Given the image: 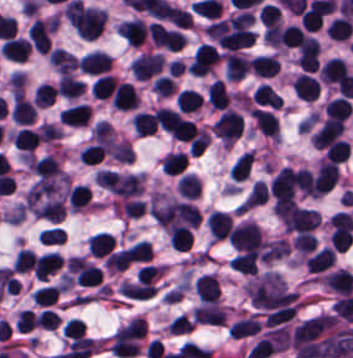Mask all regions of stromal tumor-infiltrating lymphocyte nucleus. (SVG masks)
<instances>
[{
    "mask_svg": "<svg viewBox=\"0 0 353 358\" xmlns=\"http://www.w3.org/2000/svg\"><path fill=\"white\" fill-rule=\"evenodd\" d=\"M58 325V315L50 309H43L38 315L37 326L43 329H56Z\"/></svg>",
    "mask_w": 353,
    "mask_h": 358,
    "instance_id": "4aeada98",
    "label": "stromal tumor-infiltrating lymphocyte nucleus"
},
{
    "mask_svg": "<svg viewBox=\"0 0 353 358\" xmlns=\"http://www.w3.org/2000/svg\"><path fill=\"white\" fill-rule=\"evenodd\" d=\"M116 81L110 74H102L97 78L91 88V94L96 98H110Z\"/></svg>",
    "mask_w": 353,
    "mask_h": 358,
    "instance_id": "16295066",
    "label": "stromal tumor-infiltrating lymphocyte nucleus"
},
{
    "mask_svg": "<svg viewBox=\"0 0 353 358\" xmlns=\"http://www.w3.org/2000/svg\"><path fill=\"white\" fill-rule=\"evenodd\" d=\"M339 170L335 163L329 160L321 161L313 182L314 196H322L335 184Z\"/></svg>",
    "mask_w": 353,
    "mask_h": 358,
    "instance_id": "4f13568d",
    "label": "stromal tumor-infiltrating lymphocyte nucleus"
},
{
    "mask_svg": "<svg viewBox=\"0 0 353 358\" xmlns=\"http://www.w3.org/2000/svg\"><path fill=\"white\" fill-rule=\"evenodd\" d=\"M164 63L162 54L143 52L132 62V71L137 80H146L157 74Z\"/></svg>",
    "mask_w": 353,
    "mask_h": 358,
    "instance_id": "9ea309e8",
    "label": "stromal tumor-infiltrating lymphocyte nucleus"
},
{
    "mask_svg": "<svg viewBox=\"0 0 353 358\" xmlns=\"http://www.w3.org/2000/svg\"><path fill=\"white\" fill-rule=\"evenodd\" d=\"M221 58L220 51L209 44L197 48L188 64L192 75H205Z\"/></svg>",
    "mask_w": 353,
    "mask_h": 358,
    "instance_id": "3290ff9b",
    "label": "stromal tumor-infiltrating lymphocyte nucleus"
},
{
    "mask_svg": "<svg viewBox=\"0 0 353 358\" xmlns=\"http://www.w3.org/2000/svg\"><path fill=\"white\" fill-rule=\"evenodd\" d=\"M106 153L101 143H94L80 150L79 157L86 164H96L101 161Z\"/></svg>",
    "mask_w": 353,
    "mask_h": 358,
    "instance_id": "894b7857",
    "label": "stromal tumor-infiltrating lymphocyte nucleus"
},
{
    "mask_svg": "<svg viewBox=\"0 0 353 358\" xmlns=\"http://www.w3.org/2000/svg\"><path fill=\"white\" fill-rule=\"evenodd\" d=\"M111 60L106 51L94 50L79 60V67L86 73L101 75L110 71Z\"/></svg>",
    "mask_w": 353,
    "mask_h": 358,
    "instance_id": "4803ca6d",
    "label": "stromal tumor-infiltrating lymphocyte nucleus"
},
{
    "mask_svg": "<svg viewBox=\"0 0 353 358\" xmlns=\"http://www.w3.org/2000/svg\"><path fill=\"white\" fill-rule=\"evenodd\" d=\"M35 321L34 313L29 309H22L16 318V329L30 331Z\"/></svg>",
    "mask_w": 353,
    "mask_h": 358,
    "instance_id": "d76ffc17",
    "label": "stromal tumor-infiltrating lymphocyte nucleus"
},
{
    "mask_svg": "<svg viewBox=\"0 0 353 358\" xmlns=\"http://www.w3.org/2000/svg\"><path fill=\"white\" fill-rule=\"evenodd\" d=\"M202 99L198 91L183 88L176 96V105L182 113H190L198 109Z\"/></svg>",
    "mask_w": 353,
    "mask_h": 358,
    "instance_id": "023d44f5",
    "label": "stromal tumor-infiltrating lymphocyte nucleus"
},
{
    "mask_svg": "<svg viewBox=\"0 0 353 358\" xmlns=\"http://www.w3.org/2000/svg\"><path fill=\"white\" fill-rule=\"evenodd\" d=\"M353 106L349 97L338 96L327 106V115L329 118L347 119L349 118Z\"/></svg>",
    "mask_w": 353,
    "mask_h": 358,
    "instance_id": "afbf053c",
    "label": "stromal tumor-infiltrating lymphocyte nucleus"
},
{
    "mask_svg": "<svg viewBox=\"0 0 353 358\" xmlns=\"http://www.w3.org/2000/svg\"><path fill=\"white\" fill-rule=\"evenodd\" d=\"M262 328L257 315H250L234 323L228 330L230 337L244 338L255 335Z\"/></svg>",
    "mask_w": 353,
    "mask_h": 358,
    "instance_id": "7eef579d",
    "label": "stromal tumor-infiltrating lymphocyte nucleus"
},
{
    "mask_svg": "<svg viewBox=\"0 0 353 358\" xmlns=\"http://www.w3.org/2000/svg\"><path fill=\"white\" fill-rule=\"evenodd\" d=\"M251 113L262 133L278 138V121L275 114L261 108H254Z\"/></svg>",
    "mask_w": 353,
    "mask_h": 358,
    "instance_id": "a0a3295f",
    "label": "stromal tumor-infiltrating lymphocyte nucleus"
},
{
    "mask_svg": "<svg viewBox=\"0 0 353 358\" xmlns=\"http://www.w3.org/2000/svg\"><path fill=\"white\" fill-rule=\"evenodd\" d=\"M194 289L202 303L219 300V282L211 273H204L195 278Z\"/></svg>",
    "mask_w": 353,
    "mask_h": 358,
    "instance_id": "4c9ddf68",
    "label": "stromal tumor-infiltrating lymphocyte nucleus"
},
{
    "mask_svg": "<svg viewBox=\"0 0 353 358\" xmlns=\"http://www.w3.org/2000/svg\"><path fill=\"white\" fill-rule=\"evenodd\" d=\"M14 145L24 150H34L41 138L35 129L22 128L12 136Z\"/></svg>",
    "mask_w": 353,
    "mask_h": 358,
    "instance_id": "84afeb40",
    "label": "stromal tumor-infiltrating lymphocyte nucleus"
},
{
    "mask_svg": "<svg viewBox=\"0 0 353 358\" xmlns=\"http://www.w3.org/2000/svg\"><path fill=\"white\" fill-rule=\"evenodd\" d=\"M31 47L27 40L19 36H12L0 45L3 57L14 61H25Z\"/></svg>",
    "mask_w": 353,
    "mask_h": 358,
    "instance_id": "42bb06b2",
    "label": "stromal tumor-infiltrating lymphocyte nucleus"
},
{
    "mask_svg": "<svg viewBox=\"0 0 353 358\" xmlns=\"http://www.w3.org/2000/svg\"><path fill=\"white\" fill-rule=\"evenodd\" d=\"M116 240L110 232H96L89 242V248L97 257H105L115 248Z\"/></svg>",
    "mask_w": 353,
    "mask_h": 358,
    "instance_id": "6c763739",
    "label": "stromal tumor-infiltrating lymphocyte nucleus"
},
{
    "mask_svg": "<svg viewBox=\"0 0 353 358\" xmlns=\"http://www.w3.org/2000/svg\"><path fill=\"white\" fill-rule=\"evenodd\" d=\"M91 190L85 184H78L69 193V207L70 210L79 211L80 209L89 205Z\"/></svg>",
    "mask_w": 353,
    "mask_h": 358,
    "instance_id": "a6e9041d",
    "label": "stromal tumor-infiltrating lymphocyte nucleus"
},
{
    "mask_svg": "<svg viewBox=\"0 0 353 358\" xmlns=\"http://www.w3.org/2000/svg\"><path fill=\"white\" fill-rule=\"evenodd\" d=\"M160 274H162L160 266L152 265L148 263L138 268L136 272L138 283H143V284L151 280H154Z\"/></svg>",
    "mask_w": 353,
    "mask_h": 358,
    "instance_id": "0ca4a824",
    "label": "stromal tumor-infiltrating lymphocyte nucleus"
},
{
    "mask_svg": "<svg viewBox=\"0 0 353 358\" xmlns=\"http://www.w3.org/2000/svg\"><path fill=\"white\" fill-rule=\"evenodd\" d=\"M52 32L53 20L51 18H35L30 26L28 39L35 50L48 52Z\"/></svg>",
    "mask_w": 353,
    "mask_h": 358,
    "instance_id": "abfb95fc",
    "label": "stromal tumor-infiltrating lymphocyte nucleus"
},
{
    "mask_svg": "<svg viewBox=\"0 0 353 358\" xmlns=\"http://www.w3.org/2000/svg\"><path fill=\"white\" fill-rule=\"evenodd\" d=\"M56 97V88L54 85L42 83L33 95V103L37 108L50 106Z\"/></svg>",
    "mask_w": 353,
    "mask_h": 358,
    "instance_id": "ccc9de39",
    "label": "stromal tumor-infiltrating lymphocyte nucleus"
},
{
    "mask_svg": "<svg viewBox=\"0 0 353 358\" xmlns=\"http://www.w3.org/2000/svg\"><path fill=\"white\" fill-rule=\"evenodd\" d=\"M35 255L28 248H21L15 257L13 268L17 272H25L33 268Z\"/></svg>",
    "mask_w": 353,
    "mask_h": 358,
    "instance_id": "fb6c686a",
    "label": "stromal tumor-infiltrating lymphocyte nucleus"
},
{
    "mask_svg": "<svg viewBox=\"0 0 353 358\" xmlns=\"http://www.w3.org/2000/svg\"><path fill=\"white\" fill-rule=\"evenodd\" d=\"M86 323L77 318H70L63 328V335L69 338L84 336Z\"/></svg>",
    "mask_w": 353,
    "mask_h": 358,
    "instance_id": "b01e43ef",
    "label": "stromal tumor-infiltrating lymphocyte nucleus"
},
{
    "mask_svg": "<svg viewBox=\"0 0 353 358\" xmlns=\"http://www.w3.org/2000/svg\"><path fill=\"white\" fill-rule=\"evenodd\" d=\"M344 121L326 119L313 133V143L319 148H327L342 139Z\"/></svg>",
    "mask_w": 353,
    "mask_h": 358,
    "instance_id": "f3e2335f",
    "label": "stromal tumor-infiltrating lymphocyte nucleus"
},
{
    "mask_svg": "<svg viewBox=\"0 0 353 358\" xmlns=\"http://www.w3.org/2000/svg\"><path fill=\"white\" fill-rule=\"evenodd\" d=\"M292 90L296 97L314 101L319 94V84L314 76L301 72L292 82Z\"/></svg>",
    "mask_w": 353,
    "mask_h": 358,
    "instance_id": "9e4306bb",
    "label": "stromal tumor-infiltrating lymphocyte nucleus"
},
{
    "mask_svg": "<svg viewBox=\"0 0 353 358\" xmlns=\"http://www.w3.org/2000/svg\"><path fill=\"white\" fill-rule=\"evenodd\" d=\"M228 238L235 249L258 251L265 243L260 225L250 220L231 229Z\"/></svg>",
    "mask_w": 353,
    "mask_h": 358,
    "instance_id": "bc302bb0",
    "label": "stromal tumor-infiltrating lymphocyte nucleus"
},
{
    "mask_svg": "<svg viewBox=\"0 0 353 358\" xmlns=\"http://www.w3.org/2000/svg\"><path fill=\"white\" fill-rule=\"evenodd\" d=\"M85 88V82L71 74L70 72L60 76L58 85L59 96L65 98H79Z\"/></svg>",
    "mask_w": 353,
    "mask_h": 358,
    "instance_id": "3e0999b9",
    "label": "stromal tumor-infiltrating lymphocyte nucleus"
},
{
    "mask_svg": "<svg viewBox=\"0 0 353 358\" xmlns=\"http://www.w3.org/2000/svg\"><path fill=\"white\" fill-rule=\"evenodd\" d=\"M230 101V95L222 79H215L210 83L208 103L215 109H225Z\"/></svg>",
    "mask_w": 353,
    "mask_h": 358,
    "instance_id": "b6af03f8",
    "label": "stromal tumor-infiltrating lymphocyte nucleus"
},
{
    "mask_svg": "<svg viewBox=\"0 0 353 358\" xmlns=\"http://www.w3.org/2000/svg\"><path fill=\"white\" fill-rule=\"evenodd\" d=\"M253 166V155L249 151L244 152L230 169V177L235 181H242L251 173Z\"/></svg>",
    "mask_w": 353,
    "mask_h": 358,
    "instance_id": "1d375fb5",
    "label": "stromal tumor-infiltrating lymphocyte nucleus"
},
{
    "mask_svg": "<svg viewBox=\"0 0 353 358\" xmlns=\"http://www.w3.org/2000/svg\"><path fill=\"white\" fill-rule=\"evenodd\" d=\"M349 155V141L344 139H337L328 145L324 158L343 163Z\"/></svg>",
    "mask_w": 353,
    "mask_h": 358,
    "instance_id": "50b3126c",
    "label": "stromal tumor-infiltrating lymphocyte nucleus"
},
{
    "mask_svg": "<svg viewBox=\"0 0 353 358\" xmlns=\"http://www.w3.org/2000/svg\"><path fill=\"white\" fill-rule=\"evenodd\" d=\"M270 193L265 180H257L249 193L245 197L240 206V210H250L262 204H265L269 199Z\"/></svg>",
    "mask_w": 353,
    "mask_h": 358,
    "instance_id": "cac63f63",
    "label": "stromal tumor-infiltrating lymphocyte nucleus"
},
{
    "mask_svg": "<svg viewBox=\"0 0 353 358\" xmlns=\"http://www.w3.org/2000/svg\"><path fill=\"white\" fill-rule=\"evenodd\" d=\"M116 32L131 46H139L148 36V25L141 19H127L116 25Z\"/></svg>",
    "mask_w": 353,
    "mask_h": 358,
    "instance_id": "2a367800",
    "label": "stromal tumor-infiltrating lymphocyte nucleus"
},
{
    "mask_svg": "<svg viewBox=\"0 0 353 358\" xmlns=\"http://www.w3.org/2000/svg\"><path fill=\"white\" fill-rule=\"evenodd\" d=\"M90 110L84 103H77L63 108L60 119L69 125H86Z\"/></svg>",
    "mask_w": 353,
    "mask_h": 358,
    "instance_id": "21d57d70",
    "label": "stromal tumor-infiltrating lymphocyte nucleus"
},
{
    "mask_svg": "<svg viewBox=\"0 0 353 358\" xmlns=\"http://www.w3.org/2000/svg\"><path fill=\"white\" fill-rule=\"evenodd\" d=\"M63 263L62 258L56 251H49L38 257H35L33 270L35 278L47 279Z\"/></svg>",
    "mask_w": 353,
    "mask_h": 358,
    "instance_id": "2761f720",
    "label": "stromal tumor-infiltrating lymphocyte nucleus"
},
{
    "mask_svg": "<svg viewBox=\"0 0 353 358\" xmlns=\"http://www.w3.org/2000/svg\"><path fill=\"white\" fill-rule=\"evenodd\" d=\"M249 67L253 73L262 77H273L281 70L276 55H256L250 59Z\"/></svg>",
    "mask_w": 353,
    "mask_h": 358,
    "instance_id": "04cf8593",
    "label": "stromal tumor-infiltrating lymphocyte nucleus"
},
{
    "mask_svg": "<svg viewBox=\"0 0 353 358\" xmlns=\"http://www.w3.org/2000/svg\"><path fill=\"white\" fill-rule=\"evenodd\" d=\"M257 254L252 249H247L240 254L236 255L230 262V266L246 274H255Z\"/></svg>",
    "mask_w": 353,
    "mask_h": 358,
    "instance_id": "18da8d3c",
    "label": "stromal tumor-infiltrating lymphocyte nucleus"
},
{
    "mask_svg": "<svg viewBox=\"0 0 353 358\" xmlns=\"http://www.w3.org/2000/svg\"><path fill=\"white\" fill-rule=\"evenodd\" d=\"M60 293V287L55 284H48L34 291L32 299L40 306H48L55 302Z\"/></svg>",
    "mask_w": 353,
    "mask_h": 358,
    "instance_id": "c8d0df70",
    "label": "stromal tumor-infiltrating lymphocyte nucleus"
},
{
    "mask_svg": "<svg viewBox=\"0 0 353 358\" xmlns=\"http://www.w3.org/2000/svg\"><path fill=\"white\" fill-rule=\"evenodd\" d=\"M244 116L228 108L214 121V134L221 140L235 141L240 137Z\"/></svg>",
    "mask_w": 353,
    "mask_h": 358,
    "instance_id": "52c7bb5b",
    "label": "stromal tumor-infiltrating lymphocyte nucleus"
},
{
    "mask_svg": "<svg viewBox=\"0 0 353 358\" xmlns=\"http://www.w3.org/2000/svg\"><path fill=\"white\" fill-rule=\"evenodd\" d=\"M78 61L75 54L58 46L49 52V62L65 75L76 68Z\"/></svg>",
    "mask_w": 353,
    "mask_h": 358,
    "instance_id": "e9af9c67",
    "label": "stromal tumor-infiltrating lymphocyte nucleus"
},
{
    "mask_svg": "<svg viewBox=\"0 0 353 358\" xmlns=\"http://www.w3.org/2000/svg\"><path fill=\"white\" fill-rule=\"evenodd\" d=\"M119 289L128 298L146 299L156 294L157 287L143 282L124 280Z\"/></svg>",
    "mask_w": 353,
    "mask_h": 358,
    "instance_id": "c26a33f6",
    "label": "stromal tumor-infiltrating lymphocyte nucleus"
},
{
    "mask_svg": "<svg viewBox=\"0 0 353 358\" xmlns=\"http://www.w3.org/2000/svg\"><path fill=\"white\" fill-rule=\"evenodd\" d=\"M169 242L173 248L189 251L193 244V231L187 226H173L169 234Z\"/></svg>",
    "mask_w": 353,
    "mask_h": 358,
    "instance_id": "02f42fee",
    "label": "stromal tumor-infiltrating lymphocyte nucleus"
},
{
    "mask_svg": "<svg viewBox=\"0 0 353 358\" xmlns=\"http://www.w3.org/2000/svg\"><path fill=\"white\" fill-rule=\"evenodd\" d=\"M152 254L151 242L138 241L132 247L128 267L149 262Z\"/></svg>",
    "mask_w": 353,
    "mask_h": 358,
    "instance_id": "7b516f1d",
    "label": "stromal tumor-infiltrating lymphocyte nucleus"
},
{
    "mask_svg": "<svg viewBox=\"0 0 353 358\" xmlns=\"http://www.w3.org/2000/svg\"><path fill=\"white\" fill-rule=\"evenodd\" d=\"M138 96L126 82H119L112 91L110 103L112 108L121 111H133Z\"/></svg>",
    "mask_w": 353,
    "mask_h": 358,
    "instance_id": "4245b91a",
    "label": "stromal tumor-infiltrating lymphocyte nucleus"
},
{
    "mask_svg": "<svg viewBox=\"0 0 353 358\" xmlns=\"http://www.w3.org/2000/svg\"><path fill=\"white\" fill-rule=\"evenodd\" d=\"M31 168L39 177L47 179L63 173L60 164L51 155L35 159L31 162Z\"/></svg>",
    "mask_w": 353,
    "mask_h": 358,
    "instance_id": "fa64b396",
    "label": "stromal tumor-infiltrating lymphocyte nucleus"
},
{
    "mask_svg": "<svg viewBox=\"0 0 353 358\" xmlns=\"http://www.w3.org/2000/svg\"><path fill=\"white\" fill-rule=\"evenodd\" d=\"M207 226L214 238H227L232 226V217L226 212L213 211L207 217Z\"/></svg>",
    "mask_w": 353,
    "mask_h": 358,
    "instance_id": "782c7336",
    "label": "stromal tumor-infiltrating lymphocyte nucleus"
},
{
    "mask_svg": "<svg viewBox=\"0 0 353 358\" xmlns=\"http://www.w3.org/2000/svg\"><path fill=\"white\" fill-rule=\"evenodd\" d=\"M175 82L172 76L159 75L153 80L152 88L161 97H168L174 92Z\"/></svg>",
    "mask_w": 353,
    "mask_h": 358,
    "instance_id": "a5eb4a43",
    "label": "stromal tumor-infiltrating lymphocyte nucleus"
},
{
    "mask_svg": "<svg viewBox=\"0 0 353 358\" xmlns=\"http://www.w3.org/2000/svg\"><path fill=\"white\" fill-rule=\"evenodd\" d=\"M171 22L179 27L188 29L193 27V17L190 11L175 5L171 14Z\"/></svg>",
    "mask_w": 353,
    "mask_h": 358,
    "instance_id": "526d6599",
    "label": "stromal tumor-infiltrating lymphocyte nucleus"
},
{
    "mask_svg": "<svg viewBox=\"0 0 353 358\" xmlns=\"http://www.w3.org/2000/svg\"><path fill=\"white\" fill-rule=\"evenodd\" d=\"M131 261V246L112 251L105 259V266L111 270H123Z\"/></svg>",
    "mask_w": 353,
    "mask_h": 358,
    "instance_id": "83f04bf1",
    "label": "stromal tumor-infiltrating lymphocyte nucleus"
},
{
    "mask_svg": "<svg viewBox=\"0 0 353 358\" xmlns=\"http://www.w3.org/2000/svg\"><path fill=\"white\" fill-rule=\"evenodd\" d=\"M334 260L335 252L333 248L323 246L306 260L308 272H322L333 266Z\"/></svg>",
    "mask_w": 353,
    "mask_h": 358,
    "instance_id": "2e467ee5",
    "label": "stromal tumor-infiltrating lymphocyte nucleus"
},
{
    "mask_svg": "<svg viewBox=\"0 0 353 358\" xmlns=\"http://www.w3.org/2000/svg\"><path fill=\"white\" fill-rule=\"evenodd\" d=\"M193 324L194 320L192 318H190L187 314L181 313L172 319L168 330L179 334L189 331Z\"/></svg>",
    "mask_w": 353,
    "mask_h": 358,
    "instance_id": "741cfc7e",
    "label": "stromal tumor-infiltrating lymphocyte nucleus"
},
{
    "mask_svg": "<svg viewBox=\"0 0 353 358\" xmlns=\"http://www.w3.org/2000/svg\"><path fill=\"white\" fill-rule=\"evenodd\" d=\"M295 184L303 194L313 196L312 172L307 168H300L295 174Z\"/></svg>",
    "mask_w": 353,
    "mask_h": 358,
    "instance_id": "57c3b739",
    "label": "stromal tumor-infiltrating lymphocyte nucleus"
},
{
    "mask_svg": "<svg viewBox=\"0 0 353 358\" xmlns=\"http://www.w3.org/2000/svg\"><path fill=\"white\" fill-rule=\"evenodd\" d=\"M132 120L137 134L147 135L157 130L151 112L137 111Z\"/></svg>",
    "mask_w": 353,
    "mask_h": 358,
    "instance_id": "6da75f8f",
    "label": "stromal tumor-infiltrating lymphocyte nucleus"
},
{
    "mask_svg": "<svg viewBox=\"0 0 353 358\" xmlns=\"http://www.w3.org/2000/svg\"><path fill=\"white\" fill-rule=\"evenodd\" d=\"M187 162V155L179 150H171L162 160V171L167 174H180L185 169Z\"/></svg>",
    "mask_w": 353,
    "mask_h": 358,
    "instance_id": "8379cbfb",
    "label": "stromal tumor-infiltrating lymphocyte nucleus"
},
{
    "mask_svg": "<svg viewBox=\"0 0 353 358\" xmlns=\"http://www.w3.org/2000/svg\"><path fill=\"white\" fill-rule=\"evenodd\" d=\"M205 29L209 36L221 45L227 31V19L219 18L207 25Z\"/></svg>",
    "mask_w": 353,
    "mask_h": 358,
    "instance_id": "83bf90d3",
    "label": "stromal tumor-infiltrating lymphocyte nucleus"
},
{
    "mask_svg": "<svg viewBox=\"0 0 353 358\" xmlns=\"http://www.w3.org/2000/svg\"><path fill=\"white\" fill-rule=\"evenodd\" d=\"M259 19L264 26L270 29L277 26L281 21L280 8L276 4H262Z\"/></svg>",
    "mask_w": 353,
    "mask_h": 358,
    "instance_id": "fc20714e",
    "label": "stromal tumor-infiltrating lymphocyte nucleus"
},
{
    "mask_svg": "<svg viewBox=\"0 0 353 358\" xmlns=\"http://www.w3.org/2000/svg\"><path fill=\"white\" fill-rule=\"evenodd\" d=\"M34 105L22 92H14L11 118L13 122L28 124L33 122Z\"/></svg>",
    "mask_w": 353,
    "mask_h": 358,
    "instance_id": "3c572f05",
    "label": "stromal tumor-infiltrating lymphocyte nucleus"
},
{
    "mask_svg": "<svg viewBox=\"0 0 353 358\" xmlns=\"http://www.w3.org/2000/svg\"><path fill=\"white\" fill-rule=\"evenodd\" d=\"M179 194L195 198L200 192V178L194 173H186L178 180Z\"/></svg>",
    "mask_w": 353,
    "mask_h": 358,
    "instance_id": "a33fdf23",
    "label": "stromal tumor-infiltrating lymphocyte nucleus"
}]
</instances>
